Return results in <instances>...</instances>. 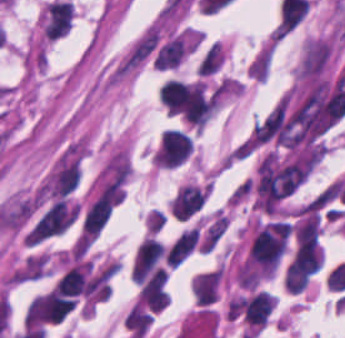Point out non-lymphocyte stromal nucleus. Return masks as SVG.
I'll return each instance as SVG.
<instances>
[{
    "label": "non-lymphocyte stromal nucleus",
    "mask_w": 345,
    "mask_h": 338,
    "mask_svg": "<svg viewBox=\"0 0 345 338\" xmlns=\"http://www.w3.org/2000/svg\"><path fill=\"white\" fill-rule=\"evenodd\" d=\"M78 214V204L65 198H58L30 230L27 240L40 241L64 231Z\"/></svg>",
    "instance_id": "obj_1"
},
{
    "label": "non-lymphocyte stromal nucleus",
    "mask_w": 345,
    "mask_h": 338,
    "mask_svg": "<svg viewBox=\"0 0 345 338\" xmlns=\"http://www.w3.org/2000/svg\"><path fill=\"white\" fill-rule=\"evenodd\" d=\"M199 228H191L183 232L166 252L167 264L178 265L188 256L197 244Z\"/></svg>",
    "instance_id": "obj_2"
}]
</instances>
